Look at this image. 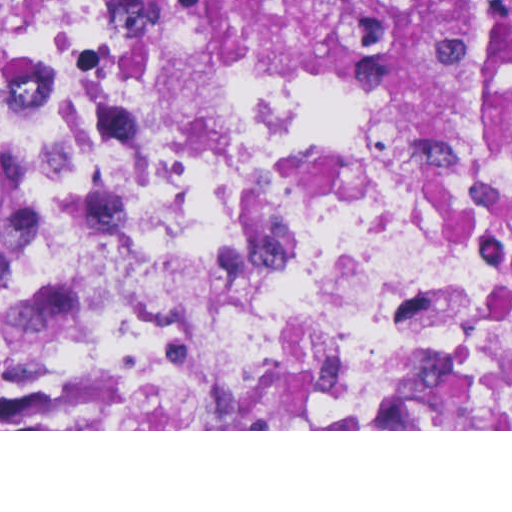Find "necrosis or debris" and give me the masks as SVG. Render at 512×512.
<instances>
[{
	"mask_svg": "<svg viewBox=\"0 0 512 512\" xmlns=\"http://www.w3.org/2000/svg\"><path fill=\"white\" fill-rule=\"evenodd\" d=\"M0 419L512 430V160L166 0H0Z\"/></svg>",
	"mask_w": 512,
	"mask_h": 512,
	"instance_id": "4bbe7bcc",
	"label": "necrosis or debris"
}]
</instances>
